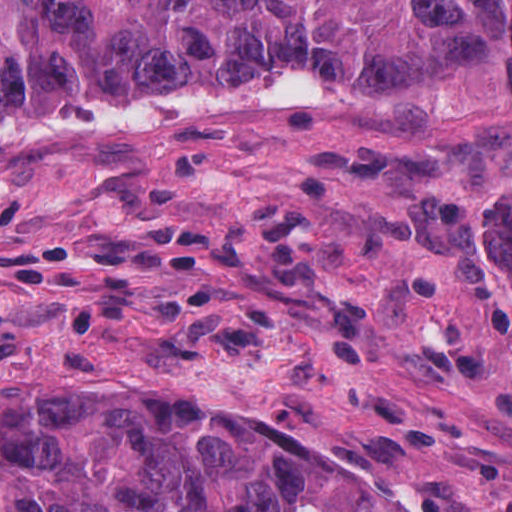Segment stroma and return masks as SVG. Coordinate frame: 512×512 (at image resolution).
Segmentation results:
<instances>
[{
    "label": "stroma",
    "mask_w": 512,
    "mask_h": 512,
    "mask_svg": "<svg viewBox=\"0 0 512 512\" xmlns=\"http://www.w3.org/2000/svg\"><path fill=\"white\" fill-rule=\"evenodd\" d=\"M309 168L0 216V400L160 412L365 481L387 512H512L498 194L346 216Z\"/></svg>",
    "instance_id": "obj_1"
}]
</instances>
